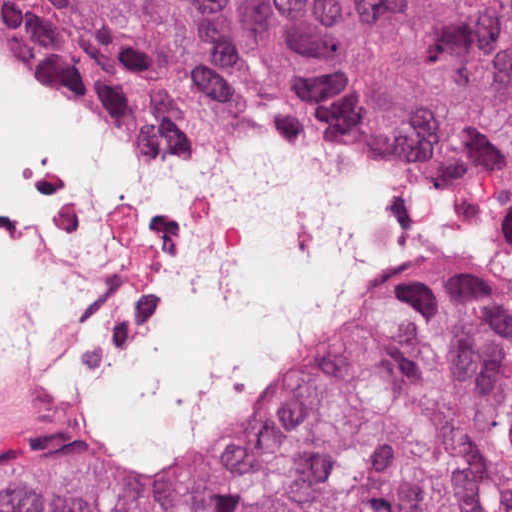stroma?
I'll return each instance as SVG.
<instances>
[{
  "instance_id": "obj_1",
  "label": "stroma",
  "mask_w": 512,
  "mask_h": 512,
  "mask_svg": "<svg viewBox=\"0 0 512 512\" xmlns=\"http://www.w3.org/2000/svg\"><path fill=\"white\" fill-rule=\"evenodd\" d=\"M0 45L19 56L21 59L39 64L60 78L76 86L97 102L110 116L125 128L149 137L157 138L162 136L178 134L164 126L154 118L126 105L108 92L104 91L89 78L66 64L59 63L21 46L0 36Z\"/></svg>"
}]
</instances>
